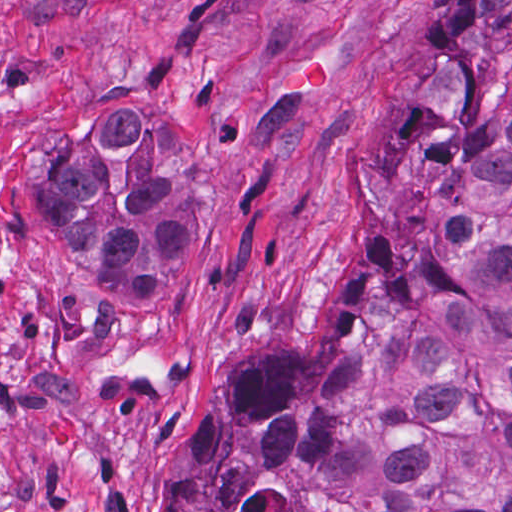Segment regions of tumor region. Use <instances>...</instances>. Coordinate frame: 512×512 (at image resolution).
Wrapping results in <instances>:
<instances>
[{
	"label": "tumor region",
	"mask_w": 512,
	"mask_h": 512,
	"mask_svg": "<svg viewBox=\"0 0 512 512\" xmlns=\"http://www.w3.org/2000/svg\"><path fill=\"white\" fill-rule=\"evenodd\" d=\"M431 76L386 136L375 223L301 342L222 363L160 512H512V0H443ZM172 126L114 103L24 207L107 306L162 295L209 193Z\"/></svg>",
	"instance_id": "e687c5a6"
}]
</instances>
